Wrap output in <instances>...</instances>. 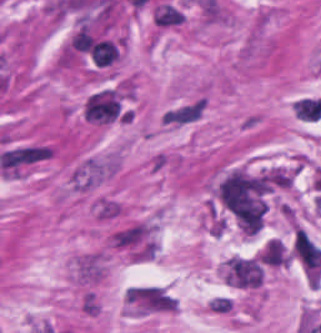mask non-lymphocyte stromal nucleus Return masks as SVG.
Instances as JSON below:
<instances>
[{
  "label": "non-lymphocyte stromal nucleus",
  "mask_w": 321,
  "mask_h": 333,
  "mask_svg": "<svg viewBox=\"0 0 321 333\" xmlns=\"http://www.w3.org/2000/svg\"><path fill=\"white\" fill-rule=\"evenodd\" d=\"M124 309L131 315L171 313L178 309V297L161 283H135L124 287Z\"/></svg>",
  "instance_id": "1"
},
{
  "label": "non-lymphocyte stromal nucleus",
  "mask_w": 321,
  "mask_h": 333,
  "mask_svg": "<svg viewBox=\"0 0 321 333\" xmlns=\"http://www.w3.org/2000/svg\"><path fill=\"white\" fill-rule=\"evenodd\" d=\"M263 266L255 256L231 255L224 263L223 279L239 287H258Z\"/></svg>",
  "instance_id": "2"
},
{
  "label": "non-lymphocyte stromal nucleus",
  "mask_w": 321,
  "mask_h": 333,
  "mask_svg": "<svg viewBox=\"0 0 321 333\" xmlns=\"http://www.w3.org/2000/svg\"><path fill=\"white\" fill-rule=\"evenodd\" d=\"M204 103L200 99H193L176 107L170 108L163 115L168 124H181L192 119L203 109Z\"/></svg>",
  "instance_id": "3"
},
{
  "label": "non-lymphocyte stromal nucleus",
  "mask_w": 321,
  "mask_h": 333,
  "mask_svg": "<svg viewBox=\"0 0 321 333\" xmlns=\"http://www.w3.org/2000/svg\"><path fill=\"white\" fill-rule=\"evenodd\" d=\"M155 25L173 26L183 21L181 8L171 1H158L154 8Z\"/></svg>",
  "instance_id": "4"
}]
</instances>
